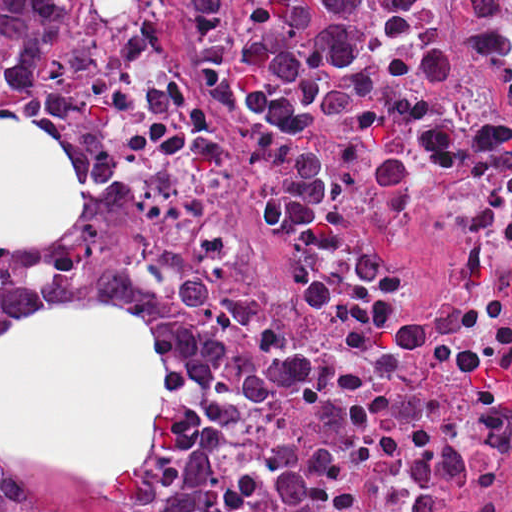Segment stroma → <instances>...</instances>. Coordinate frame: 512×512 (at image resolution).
<instances>
[{
	"instance_id": "stroma-1",
	"label": "stroma",
	"mask_w": 512,
	"mask_h": 512,
	"mask_svg": "<svg viewBox=\"0 0 512 512\" xmlns=\"http://www.w3.org/2000/svg\"><path fill=\"white\" fill-rule=\"evenodd\" d=\"M102 0H78L66 63L49 92L31 99L7 83L0 37V114L51 126L65 141L88 186L80 223L48 250H0V260L39 263L74 256L136 262L171 277L200 321V370L187 399L185 437L171 462L148 480L103 486L14 469L0 476V512H203L207 479L227 423V379L214 320L182 249L154 223L136 220L106 169L96 128V85L89 68V27Z\"/></svg>"
}]
</instances>
